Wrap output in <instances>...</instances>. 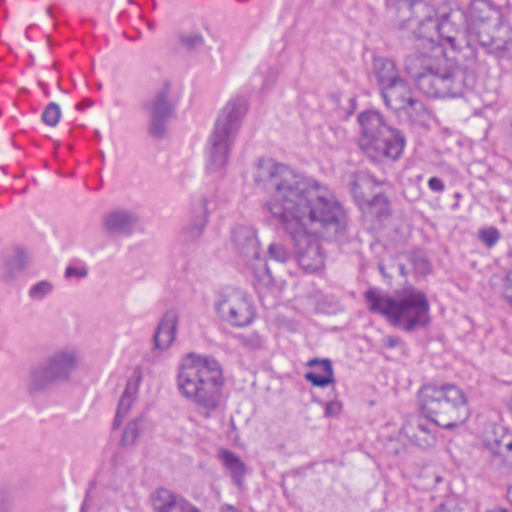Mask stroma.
Wrapping results in <instances>:
<instances>
[{"label":"stroma","mask_w":512,"mask_h":512,"mask_svg":"<svg viewBox=\"0 0 512 512\" xmlns=\"http://www.w3.org/2000/svg\"><path fill=\"white\" fill-rule=\"evenodd\" d=\"M428 1L317 0L306 21V59L249 145L220 229L191 270V290L171 326L165 391L87 512H147L158 474L179 482L205 512L225 506L204 431L174 397V374L178 357L197 349L236 357L226 338L206 331L210 290L237 264L225 240L231 223H258L269 239L276 231L265 182L284 152L335 188L359 187L366 166L354 131L358 109L393 90L382 74L394 54H413L412 18ZM509 93L512 70L489 75L481 96L441 102L430 121L434 141L452 155ZM418 358L429 372L450 376L476 411L497 414L512 366L446 315L426 319ZM246 402L262 476L257 512H421L437 494H496L504 476L477 440L420 415L364 330L309 338L301 377L257 385Z\"/></svg>","instance_id":"35a3bbf8"}]
</instances>
